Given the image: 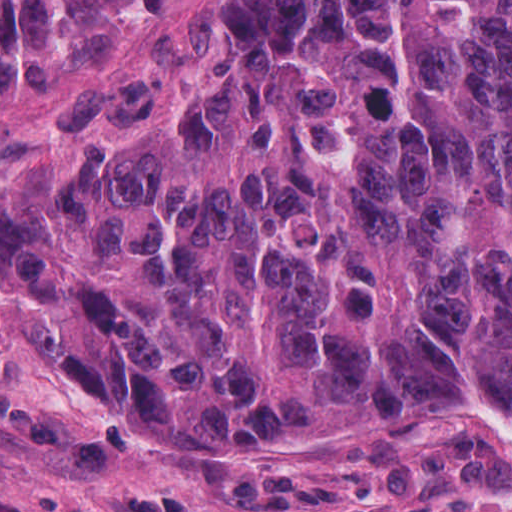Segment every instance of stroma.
Segmentation results:
<instances>
[{
  "instance_id": "1",
  "label": "stroma",
  "mask_w": 512,
  "mask_h": 512,
  "mask_svg": "<svg viewBox=\"0 0 512 512\" xmlns=\"http://www.w3.org/2000/svg\"><path fill=\"white\" fill-rule=\"evenodd\" d=\"M40 293L44 311L37 289L0 274V512H512V415L493 405L377 430L120 427L65 359Z\"/></svg>"
}]
</instances>
